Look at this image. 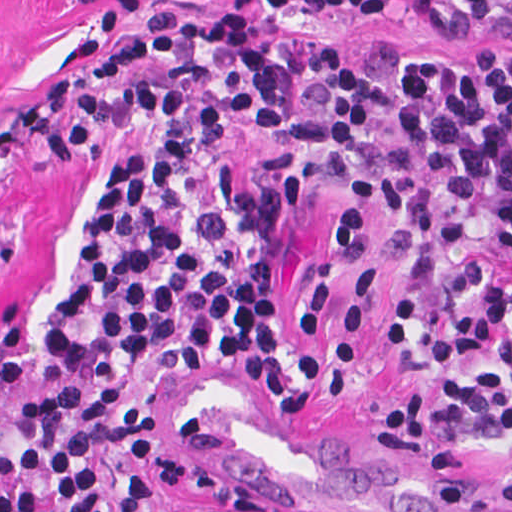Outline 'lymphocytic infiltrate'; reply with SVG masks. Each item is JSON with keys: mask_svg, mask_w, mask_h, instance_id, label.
I'll return each mask as SVG.
<instances>
[{"mask_svg": "<svg viewBox=\"0 0 512 512\" xmlns=\"http://www.w3.org/2000/svg\"><path fill=\"white\" fill-rule=\"evenodd\" d=\"M142 117L166 119L190 156L226 149L262 122L322 180L370 184L398 218L377 237L409 262L389 310L399 368L499 352L487 375H437L378 401L373 425L412 451H512V60L500 43L466 56H420L387 38L360 54L341 43L279 47L244 13L206 21L163 11L95 47L0 122V164L81 154ZM107 174L67 302L44 327L43 402L20 413L17 449L0 451V512H104V448L153 433L161 413L125 389L244 359L290 409L314 410L275 317L278 215L300 190L291 170L217 193L181 231L164 220L182 186L170 165L123 154ZM26 374L21 308L0 323V399ZM226 444L207 419L117 453L114 512H145L164 490L217 506L189 512H306L199 454ZM496 494L512 512V463Z\"/></svg>", "mask_w": 512, "mask_h": 512, "instance_id": "f902f5d3", "label": "lymphocytic infiltrate"}]
</instances>
